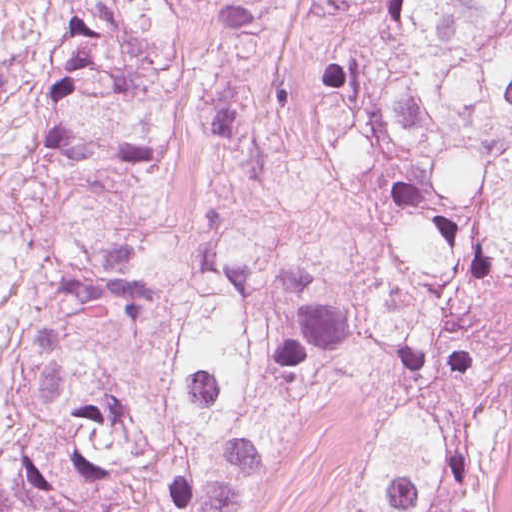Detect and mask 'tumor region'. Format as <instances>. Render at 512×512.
<instances>
[{
  "mask_svg": "<svg viewBox=\"0 0 512 512\" xmlns=\"http://www.w3.org/2000/svg\"><path fill=\"white\" fill-rule=\"evenodd\" d=\"M189 15L206 146L253 194L163 272L94 228L0 281V512H244L349 363L371 401L341 512H493L468 322L512 301V0H83L38 130L85 187L177 152Z\"/></svg>",
  "mask_w": 512,
  "mask_h": 512,
  "instance_id": "e687c5a6",
  "label": "tumor region"
}]
</instances>
